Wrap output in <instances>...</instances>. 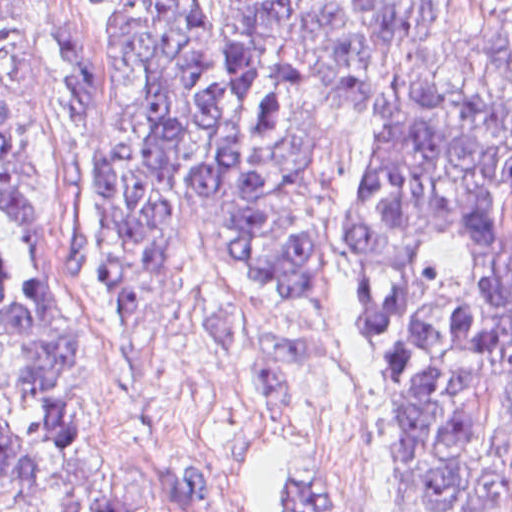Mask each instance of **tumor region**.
<instances>
[{"instance_id": "obj_1", "label": "tumor region", "mask_w": 512, "mask_h": 512, "mask_svg": "<svg viewBox=\"0 0 512 512\" xmlns=\"http://www.w3.org/2000/svg\"><path fill=\"white\" fill-rule=\"evenodd\" d=\"M104 1L107 316L200 246L237 292L322 291L326 199L373 124L350 263L395 417L376 512H512V0ZM0 390L29 432L0 426V512H38L77 376L33 0H0ZM72 512L226 507L196 467L128 462Z\"/></svg>"}]
</instances>
